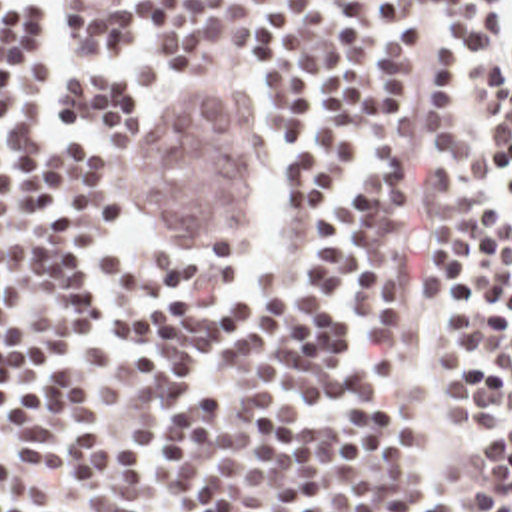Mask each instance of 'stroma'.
<instances>
[{
	"mask_svg": "<svg viewBox=\"0 0 512 512\" xmlns=\"http://www.w3.org/2000/svg\"><path fill=\"white\" fill-rule=\"evenodd\" d=\"M148 0H56V14L92 32H134ZM316 0H226L234 8ZM234 86L218 84L182 104L136 170L134 202L170 244H244L254 206V140Z\"/></svg>",
	"mask_w": 512,
	"mask_h": 512,
	"instance_id": "obj_1",
	"label": "stroma"
}]
</instances>
